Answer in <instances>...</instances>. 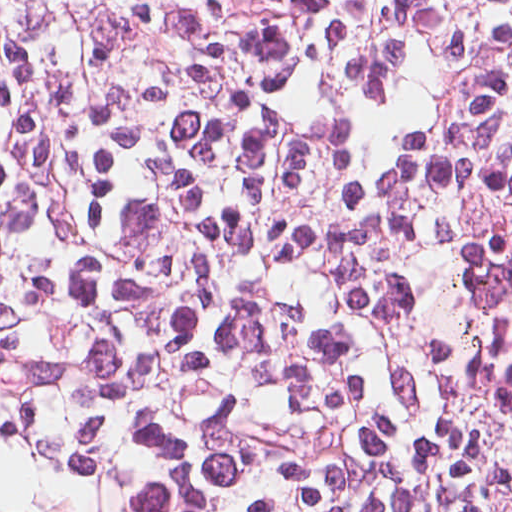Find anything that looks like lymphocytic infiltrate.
Listing matches in <instances>:
<instances>
[{
	"mask_svg": "<svg viewBox=\"0 0 512 512\" xmlns=\"http://www.w3.org/2000/svg\"><path fill=\"white\" fill-rule=\"evenodd\" d=\"M0 512H512V0H0Z\"/></svg>",
	"mask_w": 512,
	"mask_h": 512,
	"instance_id": "lymphocytic-infiltrate-1",
	"label": "lymphocytic infiltrate"
}]
</instances>
